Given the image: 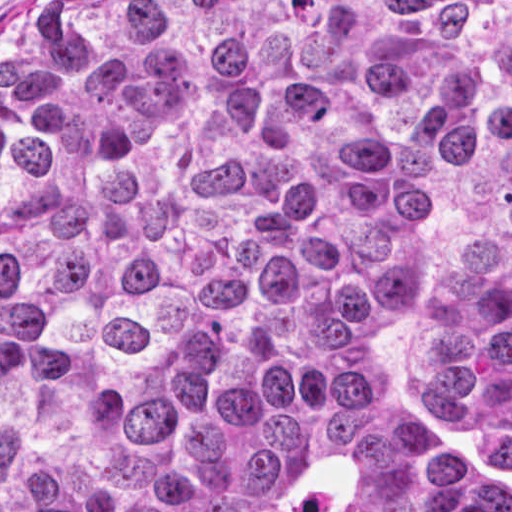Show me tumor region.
Returning <instances> with one entry per match:
<instances>
[{
    "instance_id": "1",
    "label": "tumor region",
    "mask_w": 512,
    "mask_h": 512,
    "mask_svg": "<svg viewBox=\"0 0 512 512\" xmlns=\"http://www.w3.org/2000/svg\"><path fill=\"white\" fill-rule=\"evenodd\" d=\"M0 512H512V0L15 30Z\"/></svg>"
}]
</instances>
